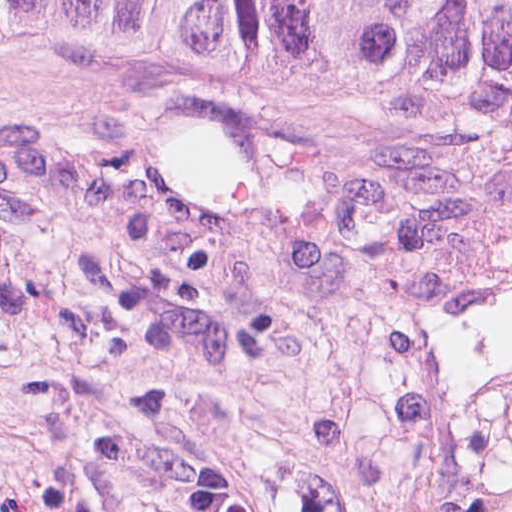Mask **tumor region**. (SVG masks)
Listing matches in <instances>:
<instances>
[{
  "instance_id": "e687c5a6",
  "label": "tumor region",
  "mask_w": 512,
  "mask_h": 512,
  "mask_svg": "<svg viewBox=\"0 0 512 512\" xmlns=\"http://www.w3.org/2000/svg\"><path fill=\"white\" fill-rule=\"evenodd\" d=\"M0 34L137 55L228 47L349 85H512V0H0Z\"/></svg>"
}]
</instances>
